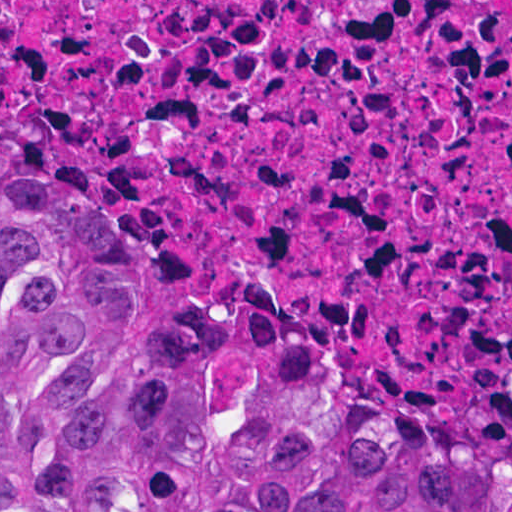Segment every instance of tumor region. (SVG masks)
Listing matches in <instances>:
<instances>
[{
	"mask_svg": "<svg viewBox=\"0 0 512 512\" xmlns=\"http://www.w3.org/2000/svg\"><path fill=\"white\" fill-rule=\"evenodd\" d=\"M0 512H512V404L189 285L0 108Z\"/></svg>",
	"mask_w": 512,
	"mask_h": 512,
	"instance_id": "obj_1",
	"label": "tumor region"
}]
</instances>
